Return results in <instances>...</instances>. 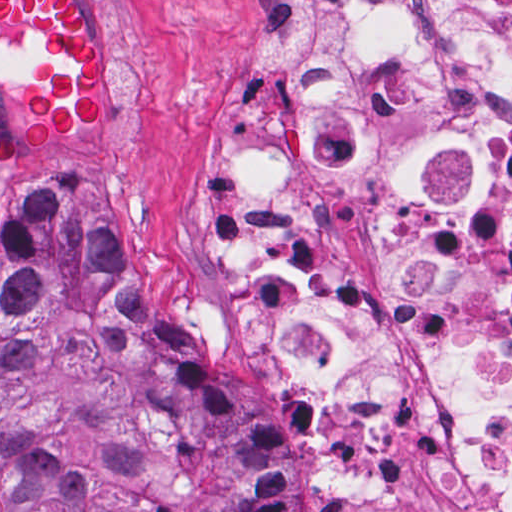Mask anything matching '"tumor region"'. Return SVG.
<instances>
[{"mask_svg": "<svg viewBox=\"0 0 512 512\" xmlns=\"http://www.w3.org/2000/svg\"><path fill=\"white\" fill-rule=\"evenodd\" d=\"M103 47L75 0H0L18 151L88 135ZM2 512H289V447L125 255L99 183L43 172L0 217Z\"/></svg>", "mask_w": 512, "mask_h": 512, "instance_id": "obj_1", "label": "tumor region"}]
</instances>
